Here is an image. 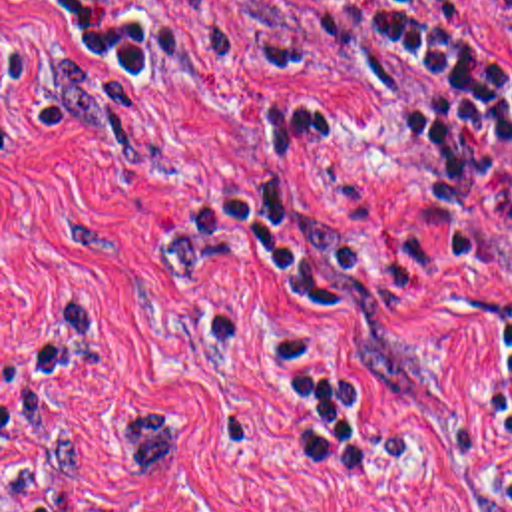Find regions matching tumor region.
I'll use <instances>...</instances> for the list:
<instances>
[{
    "label": "tumor region",
    "instance_id": "obj_1",
    "mask_svg": "<svg viewBox=\"0 0 512 512\" xmlns=\"http://www.w3.org/2000/svg\"><path fill=\"white\" fill-rule=\"evenodd\" d=\"M90 65L84 51H70L54 59L56 73L70 99V127L76 137L98 145L119 159L110 121V101L104 87L82 65ZM92 67V65H90ZM163 406L133 408L114 420V435L123 455L137 467L143 483H159L181 455V429L161 416Z\"/></svg>",
    "mask_w": 512,
    "mask_h": 512
}]
</instances>
